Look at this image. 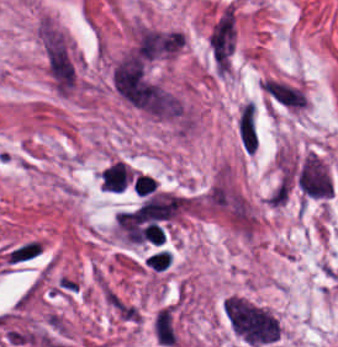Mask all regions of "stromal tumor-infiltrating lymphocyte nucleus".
I'll return each instance as SVG.
<instances>
[{
  "label": "stromal tumor-infiltrating lymphocyte nucleus",
  "instance_id": "2",
  "mask_svg": "<svg viewBox=\"0 0 338 347\" xmlns=\"http://www.w3.org/2000/svg\"><path fill=\"white\" fill-rule=\"evenodd\" d=\"M156 190V181L148 175L136 174L133 178V192L136 196H146Z\"/></svg>",
  "mask_w": 338,
  "mask_h": 347
},
{
  "label": "stromal tumor-infiltrating lymphocyte nucleus",
  "instance_id": "3",
  "mask_svg": "<svg viewBox=\"0 0 338 347\" xmlns=\"http://www.w3.org/2000/svg\"><path fill=\"white\" fill-rule=\"evenodd\" d=\"M170 253L165 249H158L150 253L144 260V265L152 270H165L169 262Z\"/></svg>",
  "mask_w": 338,
  "mask_h": 347
},
{
  "label": "stromal tumor-infiltrating lymphocyte nucleus",
  "instance_id": "1",
  "mask_svg": "<svg viewBox=\"0 0 338 347\" xmlns=\"http://www.w3.org/2000/svg\"><path fill=\"white\" fill-rule=\"evenodd\" d=\"M130 171L123 161H115L102 169L100 190L119 191L128 181Z\"/></svg>",
  "mask_w": 338,
  "mask_h": 347
}]
</instances>
